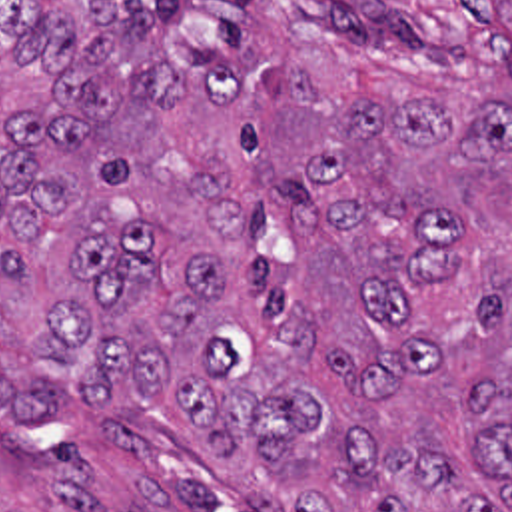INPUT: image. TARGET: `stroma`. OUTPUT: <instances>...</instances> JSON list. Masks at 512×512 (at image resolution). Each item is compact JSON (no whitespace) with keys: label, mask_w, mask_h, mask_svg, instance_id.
<instances>
[{"label":"stroma","mask_w":512,"mask_h":512,"mask_svg":"<svg viewBox=\"0 0 512 512\" xmlns=\"http://www.w3.org/2000/svg\"><path fill=\"white\" fill-rule=\"evenodd\" d=\"M0 512L296 511L251 473L0 418Z\"/></svg>","instance_id":"obj_1"}]
</instances>
